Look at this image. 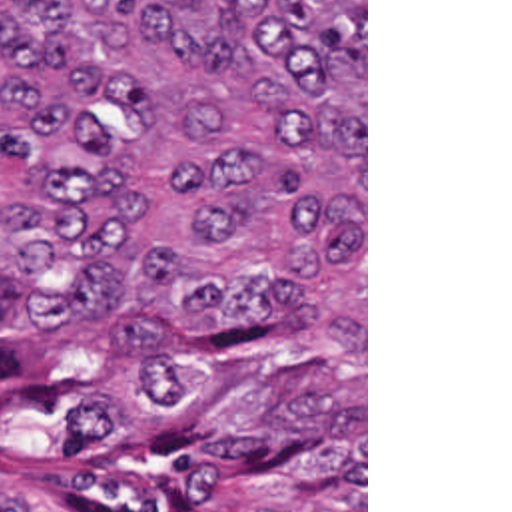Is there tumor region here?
<instances>
[{"label":"tumor region","mask_w":512,"mask_h":512,"mask_svg":"<svg viewBox=\"0 0 512 512\" xmlns=\"http://www.w3.org/2000/svg\"><path fill=\"white\" fill-rule=\"evenodd\" d=\"M0 512H364V0H0Z\"/></svg>","instance_id":"obj_1"}]
</instances>
